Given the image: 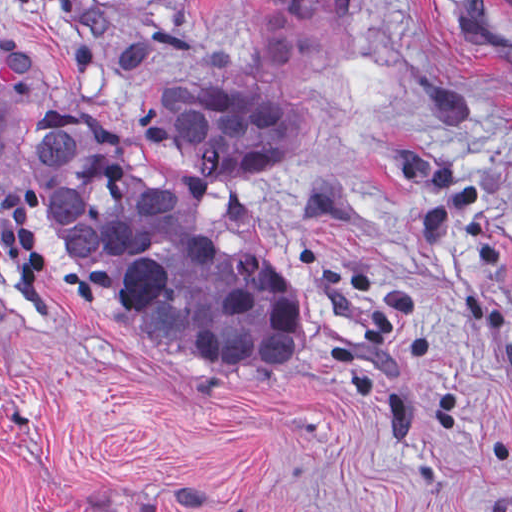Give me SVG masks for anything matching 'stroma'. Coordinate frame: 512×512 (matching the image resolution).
Returning <instances> with one entry per match:
<instances>
[{"mask_svg": "<svg viewBox=\"0 0 512 512\" xmlns=\"http://www.w3.org/2000/svg\"><path fill=\"white\" fill-rule=\"evenodd\" d=\"M76 11L222 36L210 77L301 101L242 200L302 316L259 368L93 294L1 157V32L94 123L148 113ZM0 512H512V0H0Z\"/></svg>", "mask_w": 512, "mask_h": 512, "instance_id": "stroma-1", "label": "stroma"}]
</instances>
